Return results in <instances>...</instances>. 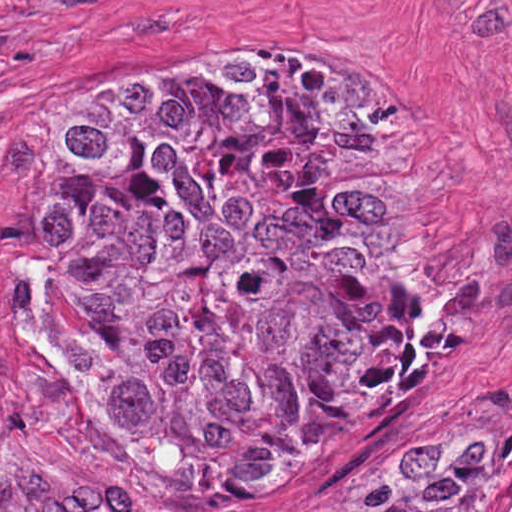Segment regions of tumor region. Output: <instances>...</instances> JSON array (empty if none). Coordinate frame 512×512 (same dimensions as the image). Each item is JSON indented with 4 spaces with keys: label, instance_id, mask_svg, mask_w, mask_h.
<instances>
[{
    "label": "tumor region",
    "instance_id": "1",
    "mask_svg": "<svg viewBox=\"0 0 512 512\" xmlns=\"http://www.w3.org/2000/svg\"><path fill=\"white\" fill-rule=\"evenodd\" d=\"M57 391L180 490L353 467L427 367L450 265L442 169L379 94L191 53L39 144ZM512 507L510 414L423 411L320 512Z\"/></svg>",
    "mask_w": 512,
    "mask_h": 512
}]
</instances>
